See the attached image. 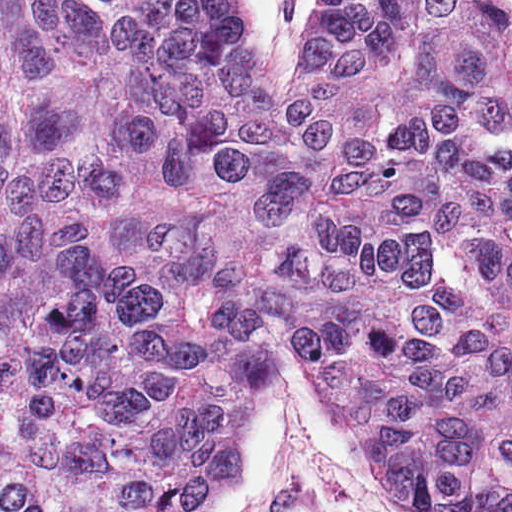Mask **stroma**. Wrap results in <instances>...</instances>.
Segmentation results:
<instances>
[{"mask_svg":"<svg viewBox=\"0 0 512 512\" xmlns=\"http://www.w3.org/2000/svg\"><path fill=\"white\" fill-rule=\"evenodd\" d=\"M512 6V0H504ZM319 0H251V52L277 96L305 51ZM381 470L343 413L332 385L284 345L273 380L241 426V471L202 512H391Z\"/></svg>","mask_w":512,"mask_h":512,"instance_id":"obj_1","label":"stroma"}]
</instances>
